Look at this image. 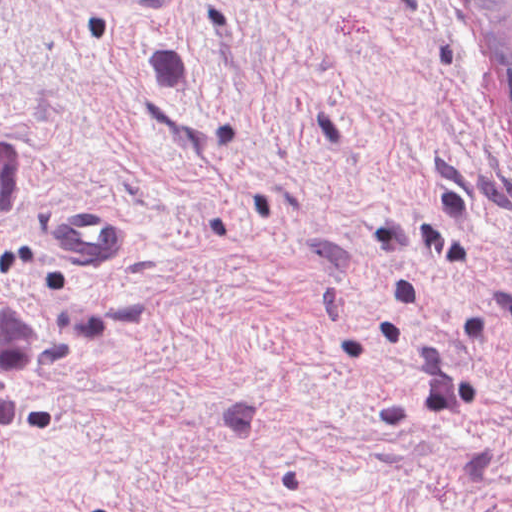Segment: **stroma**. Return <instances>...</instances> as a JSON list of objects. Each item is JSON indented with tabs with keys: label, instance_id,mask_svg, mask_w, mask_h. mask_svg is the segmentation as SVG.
Listing matches in <instances>:
<instances>
[{
	"label": "stroma",
	"instance_id": "stroma-1",
	"mask_svg": "<svg viewBox=\"0 0 512 512\" xmlns=\"http://www.w3.org/2000/svg\"><path fill=\"white\" fill-rule=\"evenodd\" d=\"M0 135V294L111 312L0 425V512H512V106L464 0H0Z\"/></svg>",
	"mask_w": 512,
	"mask_h": 512
}]
</instances>
